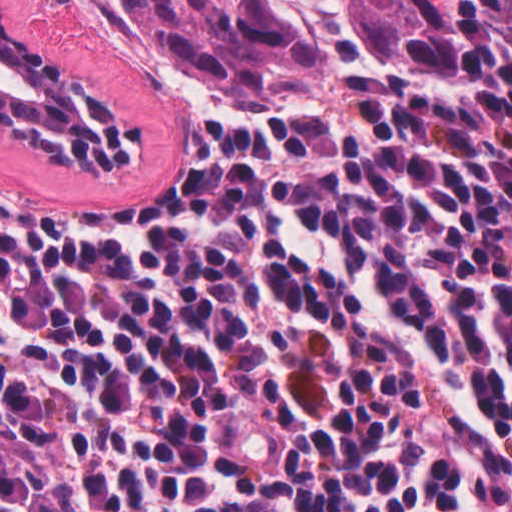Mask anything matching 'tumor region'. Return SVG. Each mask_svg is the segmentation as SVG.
I'll return each mask as SVG.
<instances>
[{
	"instance_id": "e687c5a6",
	"label": "tumor region",
	"mask_w": 512,
	"mask_h": 512,
	"mask_svg": "<svg viewBox=\"0 0 512 512\" xmlns=\"http://www.w3.org/2000/svg\"><path fill=\"white\" fill-rule=\"evenodd\" d=\"M151 71L245 95H327L449 57L462 0H100Z\"/></svg>"
}]
</instances>
